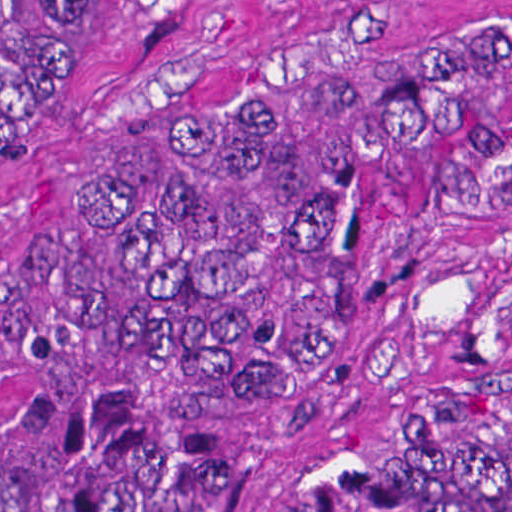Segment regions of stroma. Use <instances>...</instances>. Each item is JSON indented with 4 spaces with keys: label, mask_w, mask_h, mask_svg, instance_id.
Wrapping results in <instances>:
<instances>
[{
    "label": "stroma",
    "mask_w": 512,
    "mask_h": 512,
    "mask_svg": "<svg viewBox=\"0 0 512 512\" xmlns=\"http://www.w3.org/2000/svg\"><path fill=\"white\" fill-rule=\"evenodd\" d=\"M415 0H77L55 75L1 115V249L23 223L62 245L136 155L200 127L307 53ZM512 132V65L455 116ZM512 400V199H416L386 283L312 412Z\"/></svg>",
    "instance_id": "obj_1"
}]
</instances>
